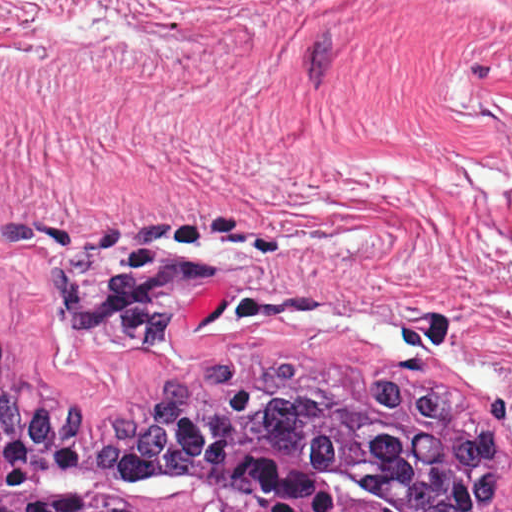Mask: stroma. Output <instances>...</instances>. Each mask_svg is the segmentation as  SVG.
Masks as SVG:
<instances>
[{"label":"stroma","instance_id":"1","mask_svg":"<svg viewBox=\"0 0 512 512\" xmlns=\"http://www.w3.org/2000/svg\"><path fill=\"white\" fill-rule=\"evenodd\" d=\"M0 335L131 418L232 357L461 391L512 507V0H0Z\"/></svg>","mask_w":512,"mask_h":512}]
</instances>
